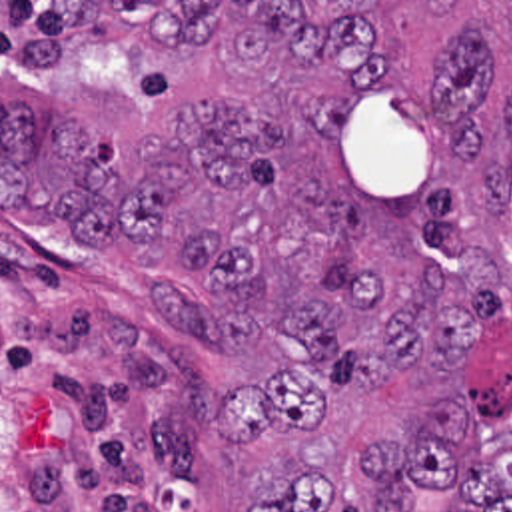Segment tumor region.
Masks as SVG:
<instances>
[{
	"instance_id": "tumor-region-1",
	"label": "tumor region",
	"mask_w": 512,
	"mask_h": 512,
	"mask_svg": "<svg viewBox=\"0 0 512 512\" xmlns=\"http://www.w3.org/2000/svg\"><path fill=\"white\" fill-rule=\"evenodd\" d=\"M235 88L112 172L74 118L0 96V208L132 244L168 327L301 359L218 395L225 445L287 427L297 477L243 512H512V2H116ZM90 40V2H0V80Z\"/></svg>"
}]
</instances>
